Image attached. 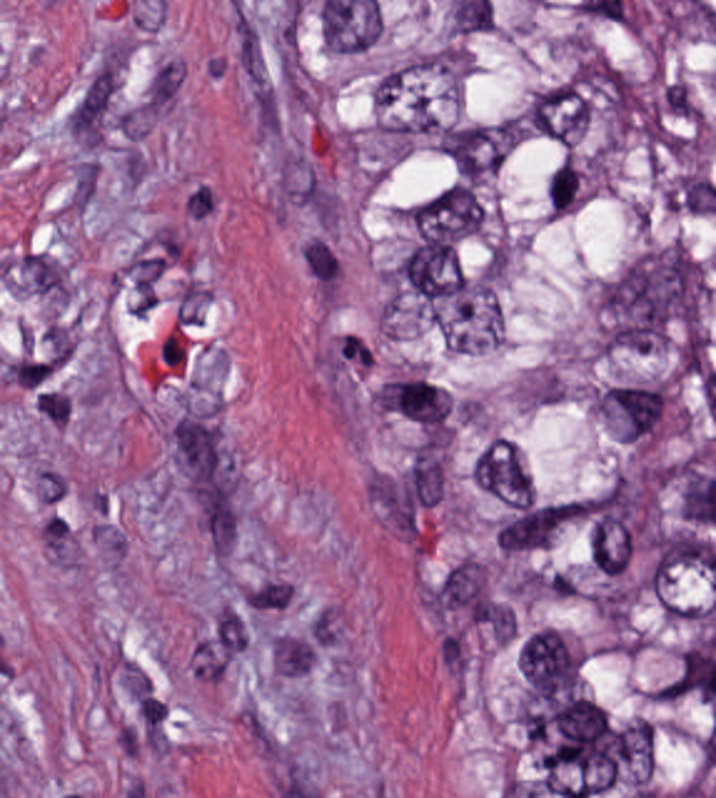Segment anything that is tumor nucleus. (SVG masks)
I'll return each instance as SVG.
<instances>
[{
  "instance_id": "tumor-nucleus-15",
  "label": "tumor nucleus",
  "mask_w": 716,
  "mask_h": 798,
  "mask_svg": "<svg viewBox=\"0 0 716 798\" xmlns=\"http://www.w3.org/2000/svg\"><path fill=\"white\" fill-rule=\"evenodd\" d=\"M518 682H569V631H518Z\"/></svg>"
},
{
  "instance_id": "tumor-nucleus-13",
  "label": "tumor nucleus",
  "mask_w": 716,
  "mask_h": 798,
  "mask_svg": "<svg viewBox=\"0 0 716 798\" xmlns=\"http://www.w3.org/2000/svg\"><path fill=\"white\" fill-rule=\"evenodd\" d=\"M543 217H584V151H543Z\"/></svg>"
},
{
  "instance_id": "tumor-nucleus-10",
  "label": "tumor nucleus",
  "mask_w": 716,
  "mask_h": 798,
  "mask_svg": "<svg viewBox=\"0 0 716 798\" xmlns=\"http://www.w3.org/2000/svg\"><path fill=\"white\" fill-rule=\"evenodd\" d=\"M468 477L473 487L508 504L534 499L527 456L507 434L496 431L485 440L471 461Z\"/></svg>"
},
{
  "instance_id": "tumor-nucleus-11",
  "label": "tumor nucleus",
  "mask_w": 716,
  "mask_h": 798,
  "mask_svg": "<svg viewBox=\"0 0 716 798\" xmlns=\"http://www.w3.org/2000/svg\"><path fill=\"white\" fill-rule=\"evenodd\" d=\"M396 285H467V239H396Z\"/></svg>"
},
{
  "instance_id": "tumor-nucleus-17",
  "label": "tumor nucleus",
  "mask_w": 716,
  "mask_h": 798,
  "mask_svg": "<svg viewBox=\"0 0 716 798\" xmlns=\"http://www.w3.org/2000/svg\"><path fill=\"white\" fill-rule=\"evenodd\" d=\"M608 786H649V726H608Z\"/></svg>"
},
{
  "instance_id": "tumor-nucleus-6",
  "label": "tumor nucleus",
  "mask_w": 716,
  "mask_h": 798,
  "mask_svg": "<svg viewBox=\"0 0 716 798\" xmlns=\"http://www.w3.org/2000/svg\"><path fill=\"white\" fill-rule=\"evenodd\" d=\"M648 622H716V546H648Z\"/></svg>"
},
{
  "instance_id": "tumor-nucleus-8",
  "label": "tumor nucleus",
  "mask_w": 716,
  "mask_h": 798,
  "mask_svg": "<svg viewBox=\"0 0 716 798\" xmlns=\"http://www.w3.org/2000/svg\"><path fill=\"white\" fill-rule=\"evenodd\" d=\"M421 240H492V184H421Z\"/></svg>"
},
{
  "instance_id": "tumor-nucleus-16",
  "label": "tumor nucleus",
  "mask_w": 716,
  "mask_h": 798,
  "mask_svg": "<svg viewBox=\"0 0 716 798\" xmlns=\"http://www.w3.org/2000/svg\"><path fill=\"white\" fill-rule=\"evenodd\" d=\"M556 739H612V693H556Z\"/></svg>"
},
{
  "instance_id": "tumor-nucleus-18",
  "label": "tumor nucleus",
  "mask_w": 716,
  "mask_h": 798,
  "mask_svg": "<svg viewBox=\"0 0 716 798\" xmlns=\"http://www.w3.org/2000/svg\"><path fill=\"white\" fill-rule=\"evenodd\" d=\"M596 582H632V516H596Z\"/></svg>"
},
{
  "instance_id": "tumor-nucleus-20",
  "label": "tumor nucleus",
  "mask_w": 716,
  "mask_h": 798,
  "mask_svg": "<svg viewBox=\"0 0 716 798\" xmlns=\"http://www.w3.org/2000/svg\"><path fill=\"white\" fill-rule=\"evenodd\" d=\"M578 796H614V746H578Z\"/></svg>"
},
{
  "instance_id": "tumor-nucleus-1",
  "label": "tumor nucleus",
  "mask_w": 716,
  "mask_h": 798,
  "mask_svg": "<svg viewBox=\"0 0 716 798\" xmlns=\"http://www.w3.org/2000/svg\"><path fill=\"white\" fill-rule=\"evenodd\" d=\"M496 547H617V486H496Z\"/></svg>"
},
{
  "instance_id": "tumor-nucleus-2",
  "label": "tumor nucleus",
  "mask_w": 716,
  "mask_h": 798,
  "mask_svg": "<svg viewBox=\"0 0 716 798\" xmlns=\"http://www.w3.org/2000/svg\"><path fill=\"white\" fill-rule=\"evenodd\" d=\"M608 315H704V239H608Z\"/></svg>"
},
{
  "instance_id": "tumor-nucleus-19",
  "label": "tumor nucleus",
  "mask_w": 716,
  "mask_h": 798,
  "mask_svg": "<svg viewBox=\"0 0 716 798\" xmlns=\"http://www.w3.org/2000/svg\"><path fill=\"white\" fill-rule=\"evenodd\" d=\"M546 798H587V748H546Z\"/></svg>"
},
{
  "instance_id": "tumor-nucleus-12",
  "label": "tumor nucleus",
  "mask_w": 716,
  "mask_h": 798,
  "mask_svg": "<svg viewBox=\"0 0 716 798\" xmlns=\"http://www.w3.org/2000/svg\"><path fill=\"white\" fill-rule=\"evenodd\" d=\"M536 142H582V82H536Z\"/></svg>"
},
{
  "instance_id": "tumor-nucleus-3",
  "label": "tumor nucleus",
  "mask_w": 716,
  "mask_h": 798,
  "mask_svg": "<svg viewBox=\"0 0 716 798\" xmlns=\"http://www.w3.org/2000/svg\"><path fill=\"white\" fill-rule=\"evenodd\" d=\"M376 135H467V59H376Z\"/></svg>"
},
{
  "instance_id": "tumor-nucleus-14",
  "label": "tumor nucleus",
  "mask_w": 716,
  "mask_h": 798,
  "mask_svg": "<svg viewBox=\"0 0 716 798\" xmlns=\"http://www.w3.org/2000/svg\"><path fill=\"white\" fill-rule=\"evenodd\" d=\"M381 335H432V284H381Z\"/></svg>"
},
{
  "instance_id": "tumor-nucleus-7",
  "label": "tumor nucleus",
  "mask_w": 716,
  "mask_h": 798,
  "mask_svg": "<svg viewBox=\"0 0 716 798\" xmlns=\"http://www.w3.org/2000/svg\"><path fill=\"white\" fill-rule=\"evenodd\" d=\"M448 185H509V119H448Z\"/></svg>"
},
{
  "instance_id": "tumor-nucleus-4",
  "label": "tumor nucleus",
  "mask_w": 716,
  "mask_h": 798,
  "mask_svg": "<svg viewBox=\"0 0 716 798\" xmlns=\"http://www.w3.org/2000/svg\"><path fill=\"white\" fill-rule=\"evenodd\" d=\"M434 357H509V281H434Z\"/></svg>"
},
{
  "instance_id": "tumor-nucleus-5",
  "label": "tumor nucleus",
  "mask_w": 716,
  "mask_h": 798,
  "mask_svg": "<svg viewBox=\"0 0 716 798\" xmlns=\"http://www.w3.org/2000/svg\"><path fill=\"white\" fill-rule=\"evenodd\" d=\"M593 382H679V321H593Z\"/></svg>"
},
{
  "instance_id": "tumor-nucleus-9",
  "label": "tumor nucleus",
  "mask_w": 716,
  "mask_h": 798,
  "mask_svg": "<svg viewBox=\"0 0 716 798\" xmlns=\"http://www.w3.org/2000/svg\"><path fill=\"white\" fill-rule=\"evenodd\" d=\"M608 444H664V379H608Z\"/></svg>"
}]
</instances>
